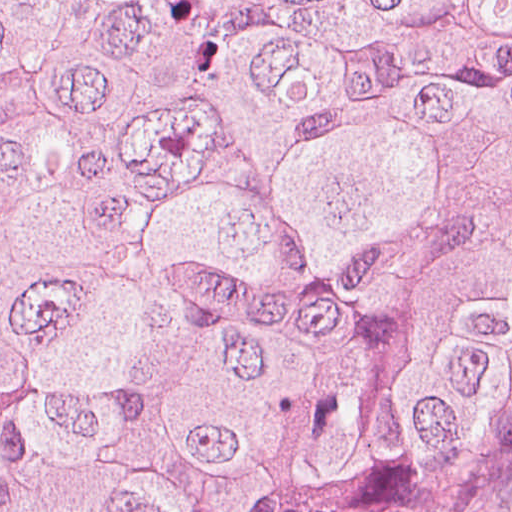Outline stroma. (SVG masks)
I'll return each mask as SVG.
<instances>
[{
    "label": "stroma",
    "mask_w": 512,
    "mask_h": 512,
    "mask_svg": "<svg viewBox=\"0 0 512 512\" xmlns=\"http://www.w3.org/2000/svg\"><path fill=\"white\" fill-rule=\"evenodd\" d=\"M477 512H512V483L486 498Z\"/></svg>",
    "instance_id": "stroma-1"
}]
</instances>
